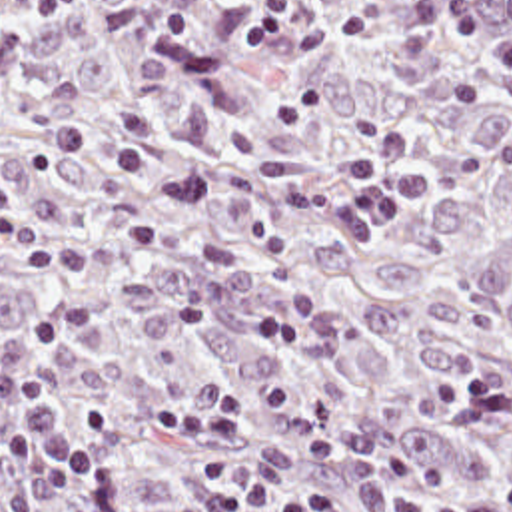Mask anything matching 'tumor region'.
I'll return each mask as SVG.
<instances>
[{
    "instance_id": "e687c5a6",
    "label": "tumor region",
    "mask_w": 512,
    "mask_h": 512,
    "mask_svg": "<svg viewBox=\"0 0 512 512\" xmlns=\"http://www.w3.org/2000/svg\"><path fill=\"white\" fill-rule=\"evenodd\" d=\"M0 215L64 265H0V337L50 309L68 418L108 402L124 462L52 512H217L207 448L157 408L233 390L225 460L341 512L512 488V0H0ZM389 127L421 197L359 241L343 157ZM10 416L0 402V446Z\"/></svg>"
}]
</instances>
